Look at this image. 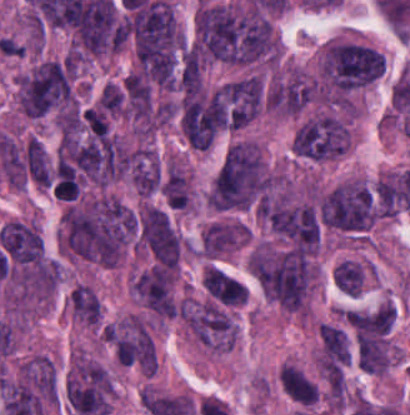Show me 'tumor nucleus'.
Segmentation results:
<instances>
[{
    "instance_id": "tumor-nucleus-1",
    "label": "tumor nucleus",
    "mask_w": 410,
    "mask_h": 415,
    "mask_svg": "<svg viewBox=\"0 0 410 415\" xmlns=\"http://www.w3.org/2000/svg\"><path fill=\"white\" fill-rule=\"evenodd\" d=\"M272 181L259 147L238 139L225 154L209 188L207 201L223 211L256 208Z\"/></svg>"
},
{
    "instance_id": "tumor-nucleus-2",
    "label": "tumor nucleus",
    "mask_w": 410,
    "mask_h": 415,
    "mask_svg": "<svg viewBox=\"0 0 410 415\" xmlns=\"http://www.w3.org/2000/svg\"><path fill=\"white\" fill-rule=\"evenodd\" d=\"M20 113L38 119L63 113L68 105V67L65 60L44 58L17 77Z\"/></svg>"
},
{
    "instance_id": "tumor-nucleus-3",
    "label": "tumor nucleus",
    "mask_w": 410,
    "mask_h": 415,
    "mask_svg": "<svg viewBox=\"0 0 410 415\" xmlns=\"http://www.w3.org/2000/svg\"><path fill=\"white\" fill-rule=\"evenodd\" d=\"M77 415H107L112 408L113 383L97 361L75 352L65 387Z\"/></svg>"
},
{
    "instance_id": "tumor-nucleus-4",
    "label": "tumor nucleus",
    "mask_w": 410,
    "mask_h": 415,
    "mask_svg": "<svg viewBox=\"0 0 410 415\" xmlns=\"http://www.w3.org/2000/svg\"><path fill=\"white\" fill-rule=\"evenodd\" d=\"M350 139L351 132L344 119L331 113H317L297 124L291 148L308 159L324 160L342 154Z\"/></svg>"
},
{
    "instance_id": "tumor-nucleus-5",
    "label": "tumor nucleus",
    "mask_w": 410,
    "mask_h": 415,
    "mask_svg": "<svg viewBox=\"0 0 410 415\" xmlns=\"http://www.w3.org/2000/svg\"><path fill=\"white\" fill-rule=\"evenodd\" d=\"M106 343L117 363L144 372H154L157 356L143 317L126 315L107 323Z\"/></svg>"
},
{
    "instance_id": "tumor-nucleus-6",
    "label": "tumor nucleus",
    "mask_w": 410,
    "mask_h": 415,
    "mask_svg": "<svg viewBox=\"0 0 410 415\" xmlns=\"http://www.w3.org/2000/svg\"><path fill=\"white\" fill-rule=\"evenodd\" d=\"M261 77L250 75L223 85L213 94L214 113L227 129H240L253 121L263 107Z\"/></svg>"
},
{
    "instance_id": "tumor-nucleus-7",
    "label": "tumor nucleus",
    "mask_w": 410,
    "mask_h": 415,
    "mask_svg": "<svg viewBox=\"0 0 410 415\" xmlns=\"http://www.w3.org/2000/svg\"><path fill=\"white\" fill-rule=\"evenodd\" d=\"M183 319L193 336L216 351H226L234 344L237 326L232 317L212 303L186 299Z\"/></svg>"
},
{
    "instance_id": "tumor-nucleus-8",
    "label": "tumor nucleus",
    "mask_w": 410,
    "mask_h": 415,
    "mask_svg": "<svg viewBox=\"0 0 410 415\" xmlns=\"http://www.w3.org/2000/svg\"><path fill=\"white\" fill-rule=\"evenodd\" d=\"M139 242L156 261L166 267L175 268L179 236L167 212L142 205L139 220Z\"/></svg>"
},
{
    "instance_id": "tumor-nucleus-9",
    "label": "tumor nucleus",
    "mask_w": 410,
    "mask_h": 415,
    "mask_svg": "<svg viewBox=\"0 0 410 415\" xmlns=\"http://www.w3.org/2000/svg\"><path fill=\"white\" fill-rule=\"evenodd\" d=\"M133 298L159 318L174 314V273L151 267L141 272L131 283Z\"/></svg>"
},
{
    "instance_id": "tumor-nucleus-10",
    "label": "tumor nucleus",
    "mask_w": 410,
    "mask_h": 415,
    "mask_svg": "<svg viewBox=\"0 0 410 415\" xmlns=\"http://www.w3.org/2000/svg\"><path fill=\"white\" fill-rule=\"evenodd\" d=\"M69 307L80 323L99 326L102 301L93 287L84 282H77L70 292Z\"/></svg>"
},
{
    "instance_id": "tumor-nucleus-11",
    "label": "tumor nucleus",
    "mask_w": 410,
    "mask_h": 415,
    "mask_svg": "<svg viewBox=\"0 0 410 415\" xmlns=\"http://www.w3.org/2000/svg\"><path fill=\"white\" fill-rule=\"evenodd\" d=\"M203 282L208 298L225 306L242 304V282L221 269L212 266Z\"/></svg>"
},
{
    "instance_id": "tumor-nucleus-12",
    "label": "tumor nucleus",
    "mask_w": 410,
    "mask_h": 415,
    "mask_svg": "<svg viewBox=\"0 0 410 415\" xmlns=\"http://www.w3.org/2000/svg\"><path fill=\"white\" fill-rule=\"evenodd\" d=\"M280 385L287 397L298 405L313 406L319 390L300 369L285 365L280 372Z\"/></svg>"
},
{
    "instance_id": "tumor-nucleus-13",
    "label": "tumor nucleus",
    "mask_w": 410,
    "mask_h": 415,
    "mask_svg": "<svg viewBox=\"0 0 410 415\" xmlns=\"http://www.w3.org/2000/svg\"><path fill=\"white\" fill-rule=\"evenodd\" d=\"M25 159L35 182L48 187L51 183V171L42 143L30 137L27 143Z\"/></svg>"
},
{
    "instance_id": "tumor-nucleus-14",
    "label": "tumor nucleus",
    "mask_w": 410,
    "mask_h": 415,
    "mask_svg": "<svg viewBox=\"0 0 410 415\" xmlns=\"http://www.w3.org/2000/svg\"><path fill=\"white\" fill-rule=\"evenodd\" d=\"M332 280L342 293L358 297L362 286L361 267L357 262L343 260L333 270Z\"/></svg>"
}]
</instances>
